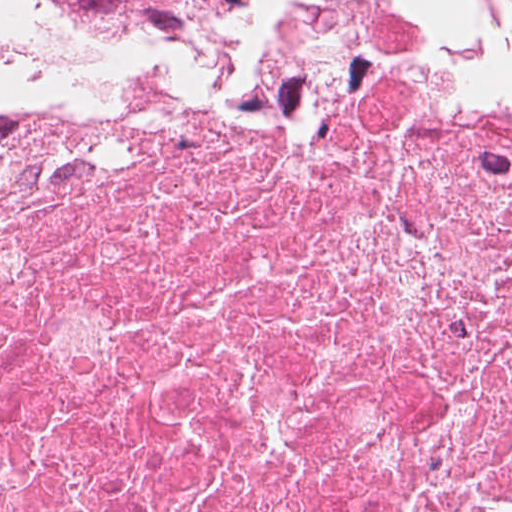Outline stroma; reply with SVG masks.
I'll return each instance as SVG.
<instances>
[{
  "instance_id": "stroma-1",
  "label": "stroma",
  "mask_w": 512,
  "mask_h": 512,
  "mask_svg": "<svg viewBox=\"0 0 512 512\" xmlns=\"http://www.w3.org/2000/svg\"><path fill=\"white\" fill-rule=\"evenodd\" d=\"M302 1L252 0L216 17L123 24L34 10L8 51L0 53V89L28 80L164 71Z\"/></svg>"
}]
</instances>
